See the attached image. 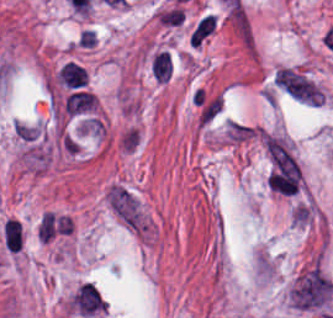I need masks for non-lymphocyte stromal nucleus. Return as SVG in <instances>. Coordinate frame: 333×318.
Listing matches in <instances>:
<instances>
[{
    "instance_id": "3",
    "label": "non-lymphocyte stromal nucleus",
    "mask_w": 333,
    "mask_h": 318,
    "mask_svg": "<svg viewBox=\"0 0 333 318\" xmlns=\"http://www.w3.org/2000/svg\"><path fill=\"white\" fill-rule=\"evenodd\" d=\"M273 81L296 100L314 105L322 103V90L296 70L280 67L277 69Z\"/></svg>"
},
{
    "instance_id": "2",
    "label": "non-lymphocyte stromal nucleus",
    "mask_w": 333,
    "mask_h": 318,
    "mask_svg": "<svg viewBox=\"0 0 333 318\" xmlns=\"http://www.w3.org/2000/svg\"><path fill=\"white\" fill-rule=\"evenodd\" d=\"M333 280L320 263L299 273L291 287L290 302L302 309H327Z\"/></svg>"
},
{
    "instance_id": "1",
    "label": "non-lymphocyte stromal nucleus",
    "mask_w": 333,
    "mask_h": 318,
    "mask_svg": "<svg viewBox=\"0 0 333 318\" xmlns=\"http://www.w3.org/2000/svg\"><path fill=\"white\" fill-rule=\"evenodd\" d=\"M106 204L116 222L130 235L146 244L152 240L154 226L138 196L125 184H111Z\"/></svg>"
},
{
    "instance_id": "4",
    "label": "non-lymphocyte stromal nucleus",
    "mask_w": 333,
    "mask_h": 318,
    "mask_svg": "<svg viewBox=\"0 0 333 318\" xmlns=\"http://www.w3.org/2000/svg\"><path fill=\"white\" fill-rule=\"evenodd\" d=\"M216 18L212 15H205L193 27L189 41L191 45H199L215 29Z\"/></svg>"
}]
</instances>
